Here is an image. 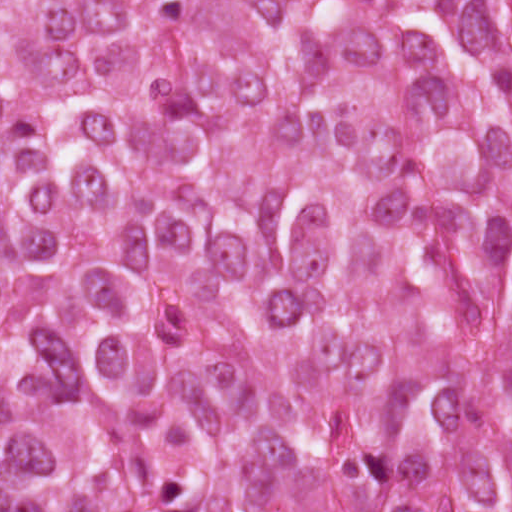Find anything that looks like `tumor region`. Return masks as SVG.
<instances>
[{
  "label": "tumor region",
  "mask_w": 512,
  "mask_h": 512,
  "mask_svg": "<svg viewBox=\"0 0 512 512\" xmlns=\"http://www.w3.org/2000/svg\"><path fill=\"white\" fill-rule=\"evenodd\" d=\"M0 512H512V0H0Z\"/></svg>",
  "instance_id": "1"
}]
</instances>
